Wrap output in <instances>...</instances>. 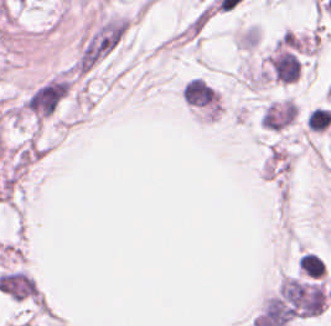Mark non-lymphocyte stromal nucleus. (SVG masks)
<instances>
[{
  "instance_id": "non-lymphocyte-stromal-nucleus-1",
  "label": "non-lymphocyte stromal nucleus",
  "mask_w": 331,
  "mask_h": 326,
  "mask_svg": "<svg viewBox=\"0 0 331 326\" xmlns=\"http://www.w3.org/2000/svg\"><path fill=\"white\" fill-rule=\"evenodd\" d=\"M296 104L289 98L270 100L260 113V124L265 127L281 130L295 117Z\"/></svg>"
}]
</instances>
